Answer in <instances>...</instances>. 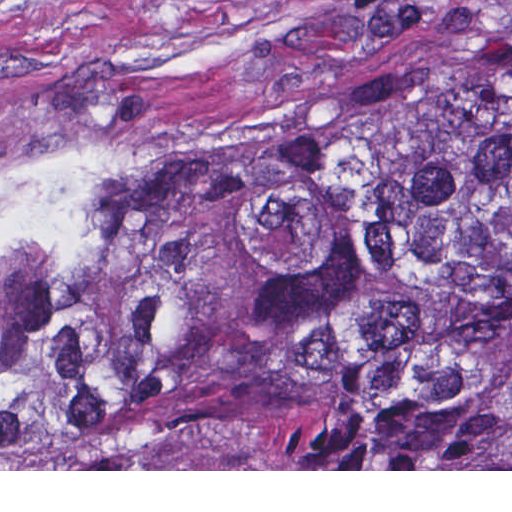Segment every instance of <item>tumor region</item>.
<instances>
[{
	"label": "tumor region",
	"mask_w": 512,
	"mask_h": 512,
	"mask_svg": "<svg viewBox=\"0 0 512 512\" xmlns=\"http://www.w3.org/2000/svg\"><path fill=\"white\" fill-rule=\"evenodd\" d=\"M1 469H512V24L14 199Z\"/></svg>",
	"instance_id": "obj_1"
}]
</instances>
